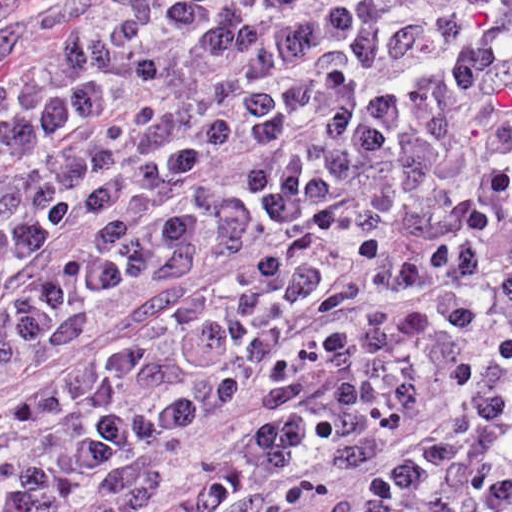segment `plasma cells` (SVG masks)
Wrapping results in <instances>:
<instances>
[{
	"mask_svg": "<svg viewBox=\"0 0 512 512\" xmlns=\"http://www.w3.org/2000/svg\"><path fill=\"white\" fill-rule=\"evenodd\" d=\"M0 512H512V0H62L0 40Z\"/></svg>",
	"mask_w": 512,
	"mask_h": 512,
	"instance_id": "obj_1",
	"label": "plasma cells"
}]
</instances>
